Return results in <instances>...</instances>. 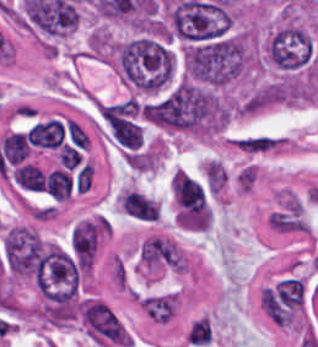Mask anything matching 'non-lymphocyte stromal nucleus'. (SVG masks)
Segmentation results:
<instances>
[{
  "instance_id": "dd21d789",
  "label": "non-lymphocyte stromal nucleus",
  "mask_w": 318,
  "mask_h": 347,
  "mask_svg": "<svg viewBox=\"0 0 318 347\" xmlns=\"http://www.w3.org/2000/svg\"><path fill=\"white\" fill-rule=\"evenodd\" d=\"M124 213L144 221L158 218L159 206L156 200L136 190L124 189L119 199Z\"/></svg>"
},
{
  "instance_id": "a72fc3eb",
  "label": "non-lymphocyte stromal nucleus",
  "mask_w": 318,
  "mask_h": 347,
  "mask_svg": "<svg viewBox=\"0 0 318 347\" xmlns=\"http://www.w3.org/2000/svg\"><path fill=\"white\" fill-rule=\"evenodd\" d=\"M185 339L190 346H206L211 339L209 321L195 319L185 332Z\"/></svg>"
}]
</instances>
